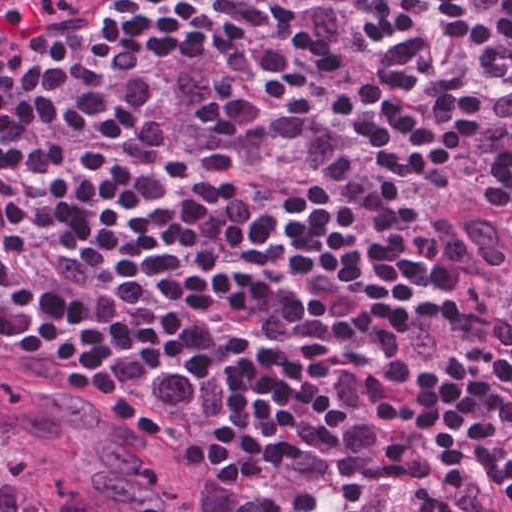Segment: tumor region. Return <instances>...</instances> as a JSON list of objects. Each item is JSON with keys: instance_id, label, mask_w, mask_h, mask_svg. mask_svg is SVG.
Segmentation results:
<instances>
[{"instance_id": "tumor-region-1", "label": "tumor region", "mask_w": 512, "mask_h": 512, "mask_svg": "<svg viewBox=\"0 0 512 512\" xmlns=\"http://www.w3.org/2000/svg\"><path fill=\"white\" fill-rule=\"evenodd\" d=\"M0 0V54L24 17ZM438 195L424 234L473 291L512 293V256L494 219L472 199ZM155 373L129 404L126 431L72 387L0 366V512H257L247 485L189 481L171 470L215 427L226 389L197 361ZM397 512H415L414 499ZM455 512H480L459 496Z\"/></svg>"}]
</instances>
